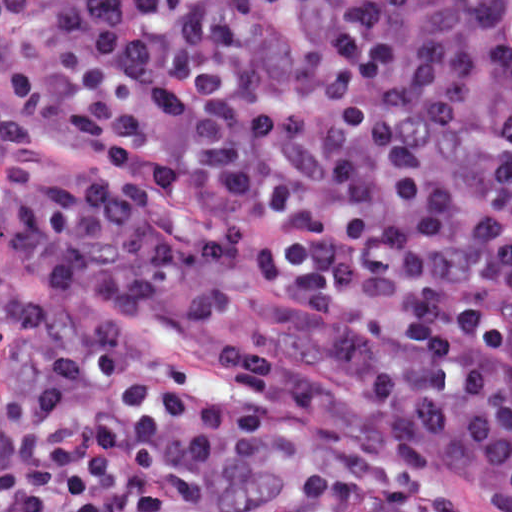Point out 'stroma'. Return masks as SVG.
Returning a JSON list of instances; mask_svg holds the SVG:
<instances>
[{"instance_id": "35a3bbf8", "label": "stroma", "mask_w": 512, "mask_h": 512, "mask_svg": "<svg viewBox=\"0 0 512 512\" xmlns=\"http://www.w3.org/2000/svg\"><path fill=\"white\" fill-rule=\"evenodd\" d=\"M0 28V105L14 106L15 94L2 76ZM265 222L248 232L237 263L223 282L224 301L200 315L133 312L62 286L0 237V266L10 284L27 290L53 310L68 314L91 313L118 319L127 325L138 342L188 366L199 386L225 385L218 363L222 352L238 349H275L321 369L327 352L306 331L286 321L280 311L241 283L256 272Z\"/></svg>"}]
</instances>
